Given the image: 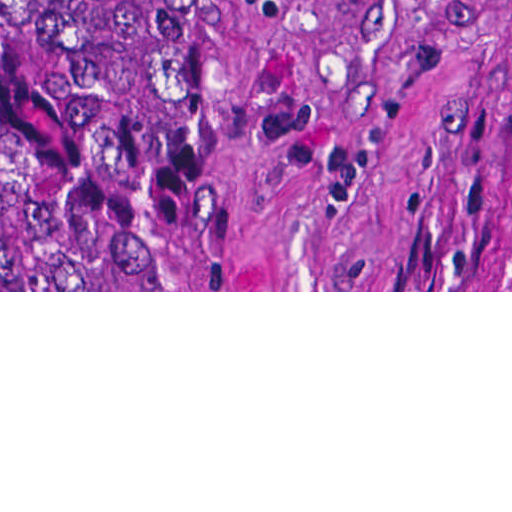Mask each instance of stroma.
<instances>
[{
    "mask_svg": "<svg viewBox=\"0 0 512 512\" xmlns=\"http://www.w3.org/2000/svg\"><path fill=\"white\" fill-rule=\"evenodd\" d=\"M0 292H512V0H188V113H0Z\"/></svg>",
    "mask_w": 512,
    "mask_h": 512,
    "instance_id": "1",
    "label": "stroma"
}]
</instances>
